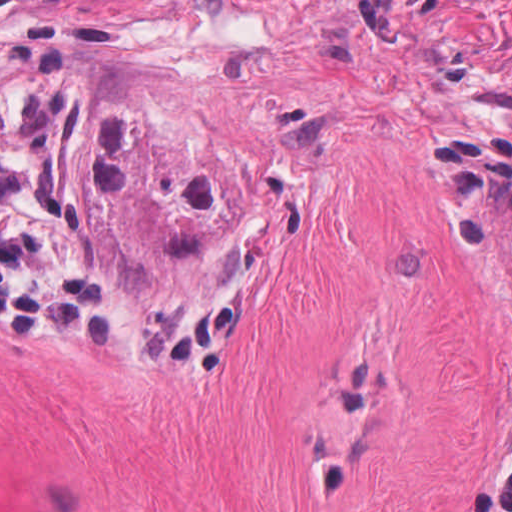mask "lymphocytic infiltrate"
Here are the masks:
<instances>
[{
  "mask_svg": "<svg viewBox=\"0 0 512 512\" xmlns=\"http://www.w3.org/2000/svg\"><path fill=\"white\" fill-rule=\"evenodd\" d=\"M242 299L223 288H110L91 254L79 92L67 72L0 81V341L76 345L168 379H220ZM470 512H512V427Z\"/></svg>",
  "mask_w": 512,
  "mask_h": 512,
  "instance_id": "lymphocytic-infiltrate-1",
  "label": "lymphocytic infiltrate"
}]
</instances>
